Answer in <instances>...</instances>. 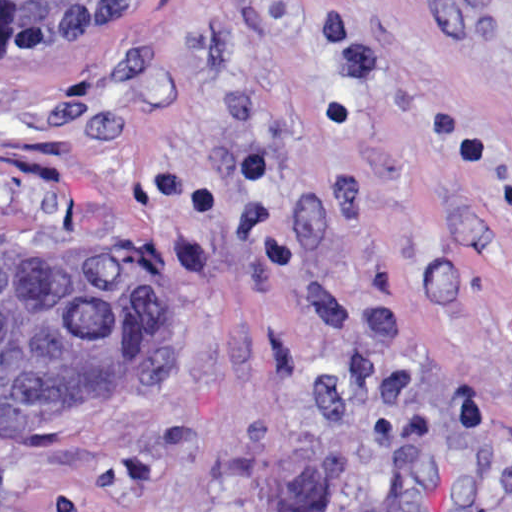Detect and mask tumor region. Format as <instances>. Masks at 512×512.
<instances>
[{"label":"tumor region","instance_id":"obj_1","mask_svg":"<svg viewBox=\"0 0 512 512\" xmlns=\"http://www.w3.org/2000/svg\"><path fill=\"white\" fill-rule=\"evenodd\" d=\"M135 0H0V47L106 28ZM189 248L142 223L92 247H0V432L122 416L179 382Z\"/></svg>","mask_w":512,"mask_h":512}]
</instances>
